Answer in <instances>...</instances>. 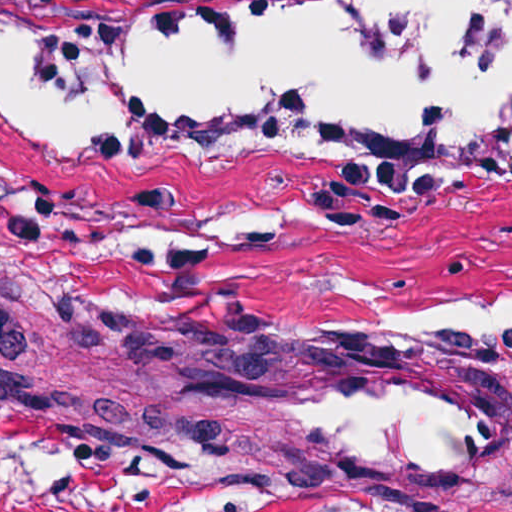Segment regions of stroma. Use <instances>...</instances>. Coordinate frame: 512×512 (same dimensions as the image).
Wrapping results in <instances>:
<instances>
[{"label":"stroma","mask_w":512,"mask_h":512,"mask_svg":"<svg viewBox=\"0 0 512 512\" xmlns=\"http://www.w3.org/2000/svg\"><path fill=\"white\" fill-rule=\"evenodd\" d=\"M327 1L0 16L263 22ZM510 280L512 180L114 177L55 168L0 123V283L142 325L0 296V512H512V352L285 332L305 297ZM320 359H399L480 391L492 455L368 479L338 469L312 427L192 380L195 365Z\"/></svg>","instance_id":"stroma-1"}]
</instances>
